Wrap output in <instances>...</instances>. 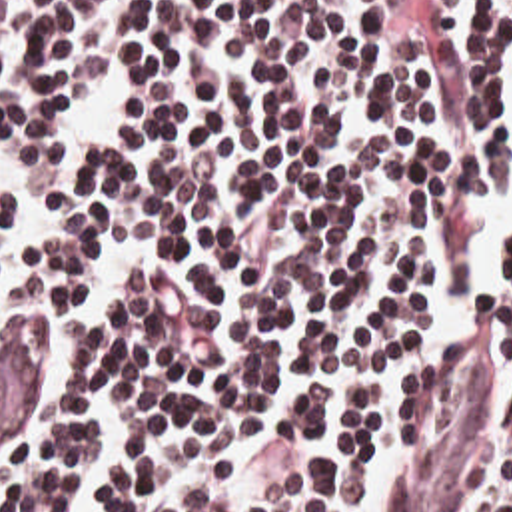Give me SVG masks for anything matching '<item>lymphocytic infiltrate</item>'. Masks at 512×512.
I'll return each instance as SVG.
<instances>
[{
	"mask_svg": "<svg viewBox=\"0 0 512 512\" xmlns=\"http://www.w3.org/2000/svg\"><path fill=\"white\" fill-rule=\"evenodd\" d=\"M512 164V0H0V330L48 366L0 512H363L473 340L512 512V250L437 240Z\"/></svg>",
	"mask_w": 512,
	"mask_h": 512,
	"instance_id": "obj_1",
	"label": "lymphocytic infiltrate"
}]
</instances>
